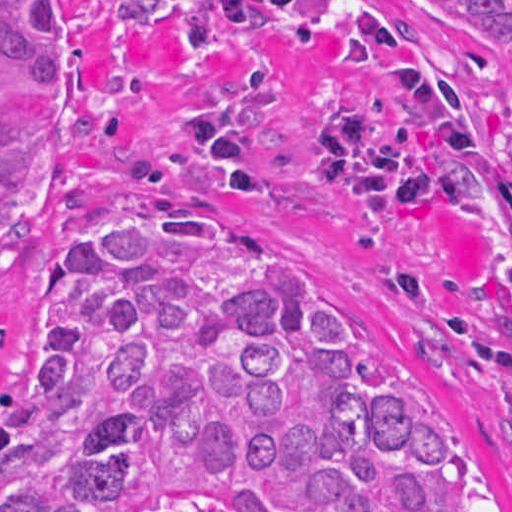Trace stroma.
I'll return each mask as SVG.
<instances>
[{
    "mask_svg": "<svg viewBox=\"0 0 512 512\" xmlns=\"http://www.w3.org/2000/svg\"><path fill=\"white\" fill-rule=\"evenodd\" d=\"M60 131L16 162L0 236V391L55 376L51 256L134 200H176L340 299L422 360L512 480V418L489 367L439 343L371 257L375 233L341 206L259 202L210 172L192 127L196 85L162 0H56Z\"/></svg>",
    "mask_w": 512,
    "mask_h": 512,
    "instance_id": "35a3bbf8",
    "label": "stroma"
}]
</instances>
